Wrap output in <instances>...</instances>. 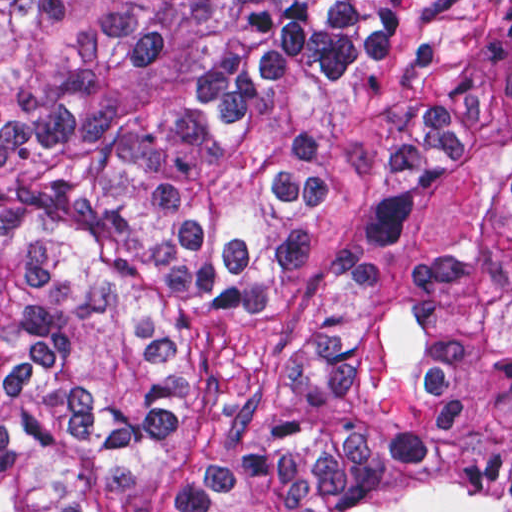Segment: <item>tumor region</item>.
<instances>
[{"instance_id": "1", "label": "tumor region", "mask_w": 512, "mask_h": 512, "mask_svg": "<svg viewBox=\"0 0 512 512\" xmlns=\"http://www.w3.org/2000/svg\"><path fill=\"white\" fill-rule=\"evenodd\" d=\"M0 512H512V1L0 0Z\"/></svg>"}]
</instances>
